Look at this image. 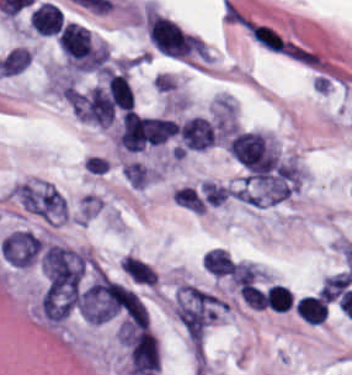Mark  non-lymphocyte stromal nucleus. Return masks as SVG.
Listing matches in <instances>:
<instances>
[{"label":"non-lymphocyte stromal nucleus","instance_id":"14","mask_svg":"<svg viewBox=\"0 0 352 375\" xmlns=\"http://www.w3.org/2000/svg\"><path fill=\"white\" fill-rule=\"evenodd\" d=\"M243 301L252 307H256L259 309H264L265 304L263 300V296L258 288L257 285L252 283H245L242 287L238 289Z\"/></svg>","mask_w":352,"mask_h":375},{"label":"non-lymphocyte stromal nucleus","instance_id":"5","mask_svg":"<svg viewBox=\"0 0 352 375\" xmlns=\"http://www.w3.org/2000/svg\"><path fill=\"white\" fill-rule=\"evenodd\" d=\"M116 138L129 152H138L145 146L142 126L135 110L125 109Z\"/></svg>","mask_w":352,"mask_h":375},{"label":"non-lymphocyte stromal nucleus","instance_id":"12","mask_svg":"<svg viewBox=\"0 0 352 375\" xmlns=\"http://www.w3.org/2000/svg\"><path fill=\"white\" fill-rule=\"evenodd\" d=\"M152 172V169L141 162H127L124 176L128 183L134 187H143Z\"/></svg>","mask_w":352,"mask_h":375},{"label":"non-lymphocyte stromal nucleus","instance_id":"7","mask_svg":"<svg viewBox=\"0 0 352 375\" xmlns=\"http://www.w3.org/2000/svg\"><path fill=\"white\" fill-rule=\"evenodd\" d=\"M106 91L114 107L127 109L134 105V95L130 83L122 73L107 70L105 72Z\"/></svg>","mask_w":352,"mask_h":375},{"label":"non-lymphocyte stromal nucleus","instance_id":"8","mask_svg":"<svg viewBox=\"0 0 352 375\" xmlns=\"http://www.w3.org/2000/svg\"><path fill=\"white\" fill-rule=\"evenodd\" d=\"M121 264L132 280L154 284L157 274L152 266L141 258L125 254L121 258Z\"/></svg>","mask_w":352,"mask_h":375},{"label":"non-lymphocyte stromal nucleus","instance_id":"3","mask_svg":"<svg viewBox=\"0 0 352 375\" xmlns=\"http://www.w3.org/2000/svg\"><path fill=\"white\" fill-rule=\"evenodd\" d=\"M73 110L82 121L93 123L110 124L115 117L110 94L95 85L73 99Z\"/></svg>","mask_w":352,"mask_h":375},{"label":"non-lymphocyte stromal nucleus","instance_id":"4","mask_svg":"<svg viewBox=\"0 0 352 375\" xmlns=\"http://www.w3.org/2000/svg\"><path fill=\"white\" fill-rule=\"evenodd\" d=\"M42 249L41 239L27 231H13L4 237L0 252L10 264H32Z\"/></svg>","mask_w":352,"mask_h":375},{"label":"non-lymphocyte stromal nucleus","instance_id":"11","mask_svg":"<svg viewBox=\"0 0 352 375\" xmlns=\"http://www.w3.org/2000/svg\"><path fill=\"white\" fill-rule=\"evenodd\" d=\"M175 201L194 212H204L205 206L194 186L183 185L172 191Z\"/></svg>","mask_w":352,"mask_h":375},{"label":"non-lymphocyte stromal nucleus","instance_id":"9","mask_svg":"<svg viewBox=\"0 0 352 375\" xmlns=\"http://www.w3.org/2000/svg\"><path fill=\"white\" fill-rule=\"evenodd\" d=\"M351 282L352 274L349 270L327 275L321 285L319 294L333 301L348 288Z\"/></svg>","mask_w":352,"mask_h":375},{"label":"non-lymphocyte stromal nucleus","instance_id":"10","mask_svg":"<svg viewBox=\"0 0 352 375\" xmlns=\"http://www.w3.org/2000/svg\"><path fill=\"white\" fill-rule=\"evenodd\" d=\"M199 188L204 200L210 205L217 206L233 192L231 186L211 179H204Z\"/></svg>","mask_w":352,"mask_h":375},{"label":"non-lymphocyte stromal nucleus","instance_id":"1","mask_svg":"<svg viewBox=\"0 0 352 375\" xmlns=\"http://www.w3.org/2000/svg\"><path fill=\"white\" fill-rule=\"evenodd\" d=\"M241 25L250 40L263 50L289 59H304L306 47L267 21L243 19Z\"/></svg>","mask_w":352,"mask_h":375},{"label":"non-lymphocyte stromal nucleus","instance_id":"13","mask_svg":"<svg viewBox=\"0 0 352 375\" xmlns=\"http://www.w3.org/2000/svg\"><path fill=\"white\" fill-rule=\"evenodd\" d=\"M259 271L257 266L249 260H236L231 276L235 282L242 285L254 282Z\"/></svg>","mask_w":352,"mask_h":375},{"label":"non-lymphocyte stromal nucleus","instance_id":"6","mask_svg":"<svg viewBox=\"0 0 352 375\" xmlns=\"http://www.w3.org/2000/svg\"><path fill=\"white\" fill-rule=\"evenodd\" d=\"M139 123L147 144H160L178 132V122L165 117L140 115Z\"/></svg>","mask_w":352,"mask_h":375},{"label":"non-lymphocyte stromal nucleus","instance_id":"2","mask_svg":"<svg viewBox=\"0 0 352 375\" xmlns=\"http://www.w3.org/2000/svg\"><path fill=\"white\" fill-rule=\"evenodd\" d=\"M19 200L26 210L48 220H67V204L62 194L45 182L20 185Z\"/></svg>","mask_w":352,"mask_h":375}]
</instances>
